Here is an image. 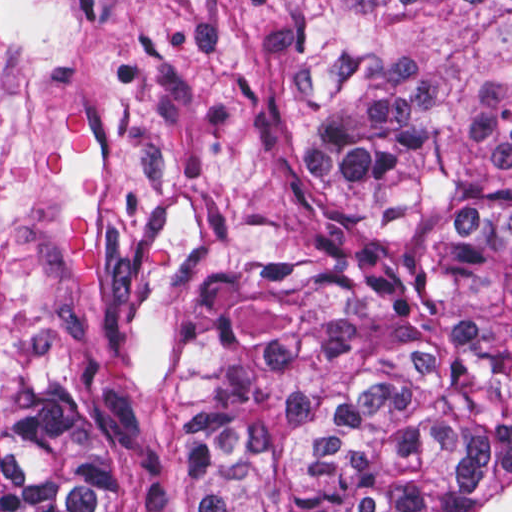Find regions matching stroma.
I'll list each match as a JSON object with an SVG mask.
<instances>
[{"label": "stroma", "mask_w": 512, "mask_h": 512, "mask_svg": "<svg viewBox=\"0 0 512 512\" xmlns=\"http://www.w3.org/2000/svg\"><path fill=\"white\" fill-rule=\"evenodd\" d=\"M304 0H0V400L138 366L241 260L314 143Z\"/></svg>", "instance_id": "stroma-1"}]
</instances>
